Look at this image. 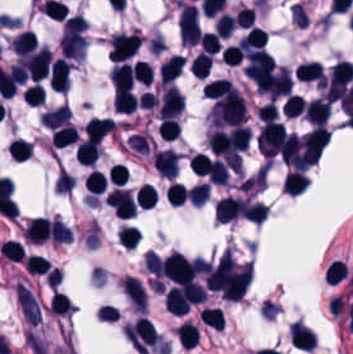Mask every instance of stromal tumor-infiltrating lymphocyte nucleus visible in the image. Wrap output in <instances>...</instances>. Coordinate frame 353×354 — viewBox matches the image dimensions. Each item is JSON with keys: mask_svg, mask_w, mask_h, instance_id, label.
Instances as JSON below:
<instances>
[{"mask_svg": "<svg viewBox=\"0 0 353 354\" xmlns=\"http://www.w3.org/2000/svg\"><path fill=\"white\" fill-rule=\"evenodd\" d=\"M177 27L180 41L184 45L192 46L200 41L202 32L195 4L180 1Z\"/></svg>", "mask_w": 353, "mask_h": 354, "instance_id": "bc302bb0", "label": "stromal tumor-infiltrating lymphocyte nucleus"}, {"mask_svg": "<svg viewBox=\"0 0 353 354\" xmlns=\"http://www.w3.org/2000/svg\"><path fill=\"white\" fill-rule=\"evenodd\" d=\"M141 40L136 32H117L111 37L109 54L113 62H122L132 57Z\"/></svg>", "mask_w": 353, "mask_h": 354, "instance_id": "52c7bb5b", "label": "stromal tumor-infiltrating lymphocyte nucleus"}, {"mask_svg": "<svg viewBox=\"0 0 353 354\" xmlns=\"http://www.w3.org/2000/svg\"><path fill=\"white\" fill-rule=\"evenodd\" d=\"M184 100L185 98L181 91L169 85L161 95L159 119H173L179 115Z\"/></svg>", "mask_w": 353, "mask_h": 354, "instance_id": "3290ff9b", "label": "stromal tumor-infiltrating lymphocyte nucleus"}, {"mask_svg": "<svg viewBox=\"0 0 353 354\" xmlns=\"http://www.w3.org/2000/svg\"><path fill=\"white\" fill-rule=\"evenodd\" d=\"M49 84L63 94L70 88V65L65 57H58L50 65Z\"/></svg>", "mask_w": 353, "mask_h": 354, "instance_id": "abfb95fc", "label": "stromal tumor-infiltrating lymphocyte nucleus"}, {"mask_svg": "<svg viewBox=\"0 0 353 354\" xmlns=\"http://www.w3.org/2000/svg\"><path fill=\"white\" fill-rule=\"evenodd\" d=\"M350 265L345 259L333 258L327 265L324 273L325 283L330 287H340L349 281Z\"/></svg>", "mask_w": 353, "mask_h": 354, "instance_id": "9ea309e8", "label": "stromal tumor-infiltrating lymphocyte nucleus"}, {"mask_svg": "<svg viewBox=\"0 0 353 354\" xmlns=\"http://www.w3.org/2000/svg\"><path fill=\"white\" fill-rule=\"evenodd\" d=\"M244 201L233 196H225L215 205V218L220 223H229L243 212Z\"/></svg>", "mask_w": 353, "mask_h": 354, "instance_id": "f3e2335f", "label": "stromal tumor-infiltrating lymphocyte nucleus"}, {"mask_svg": "<svg viewBox=\"0 0 353 354\" xmlns=\"http://www.w3.org/2000/svg\"><path fill=\"white\" fill-rule=\"evenodd\" d=\"M331 114V103L326 98H313L305 103L304 115L316 124L326 123Z\"/></svg>", "mask_w": 353, "mask_h": 354, "instance_id": "4f13568d", "label": "stromal tumor-infiltrating lymphocyte nucleus"}, {"mask_svg": "<svg viewBox=\"0 0 353 354\" xmlns=\"http://www.w3.org/2000/svg\"><path fill=\"white\" fill-rule=\"evenodd\" d=\"M26 242L41 243L50 238V222L43 218L32 219L23 229Z\"/></svg>", "mask_w": 353, "mask_h": 354, "instance_id": "2a367800", "label": "stromal tumor-infiltrating lymphocyte nucleus"}, {"mask_svg": "<svg viewBox=\"0 0 353 354\" xmlns=\"http://www.w3.org/2000/svg\"><path fill=\"white\" fill-rule=\"evenodd\" d=\"M115 122L112 118H92L87 124L85 131L87 138L97 142L104 140L113 132Z\"/></svg>", "mask_w": 353, "mask_h": 354, "instance_id": "4803ca6d", "label": "stromal tumor-infiltrating lymphocyte nucleus"}, {"mask_svg": "<svg viewBox=\"0 0 353 354\" xmlns=\"http://www.w3.org/2000/svg\"><path fill=\"white\" fill-rule=\"evenodd\" d=\"M205 98L218 99L225 96L237 94L238 90L233 86V84L223 78H215L209 80L204 88Z\"/></svg>", "mask_w": 353, "mask_h": 354, "instance_id": "4245b91a", "label": "stromal tumor-infiltrating lymphocyte nucleus"}, {"mask_svg": "<svg viewBox=\"0 0 353 354\" xmlns=\"http://www.w3.org/2000/svg\"><path fill=\"white\" fill-rule=\"evenodd\" d=\"M71 118L70 107L67 104H61L44 114H42L41 123L46 127L57 128L66 124Z\"/></svg>", "mask_w": 353, "mask_h": 354, "instance_id": "4c9ddf68", "label": "stromal tumor-infiltrating lymphocyte nucleus"}, {"mask_svg": "<svg viewBox=\"0 0 353 354\" xmlns=\"http://www.w3.org/2000/svg\"><path fill=\"white\" fill-rule=\"evenodd\" d=\"M117 91L124 92L132 84V69L129 64L118 63L109 76Z\"/></svg>", "mask_w": 353, "mask_h": 354, "instance_id": "2761f720", "label": "stromal tumor-infiltrating lymphocyte nucleus"}, {"mask_svg": "<svg viewBox=\"0 0 353 354\" xmlns=\"http://www.w3.org/2000/svg\"><path fill=\"white\" fill-rule=\"evenodd\" d=\"M36 32L32 30H25L18 34L11 41V49L16 55H24L29 51L37 48Z\"/></svg>", "mask_w": 353, "mask_h": 354, "instance_id": "3c572f05", "label": "stromal tumor-infiltrating lymphocyte nucleus"}, {"mask_svg": "<svg viewBox=\"0 0 353 354\" xmlns=\"http://www.w3.org/2000/svg\"><path fill=\"white\" fill-rule=\"evenodd\" d=\"M184 63L180 55H172L160 66L159 76L164 84H171L181 72Z\"/></svg>", "mask_w": 353, "mask_h": 354, "instance_id": "42bb06b2", "label": "stromal tumor-infiltrating lymphocyte nucleus"}, {"mask_svg": "<svg viewBox=\"0 0 353 354\" xmlns=\"http://www.w3.org/2000/svg\"><path fill=\"white\" fill-rule=\"evenodd\" d=\"M78 138L77 129L72 124H65L55 128L51 141L55 148H64L74 144Z\"/></svg>", "mask_w": 353, "mask_h": 354, "instance_id": "9e4306bb", "label": "stromal tumor-infiltrating lymphocyte nucleus"}, {"mask_svg": "<svg viewBox=\"0 0 353 354\" xmlns=\"http://www.w3.org/2000/svg\"><path fill=\"white\" fill-rule=\"evenodd\" d=\"M310 180L303 171H290L284 179L287 194L301 195L307 188Z\"/></svg>", "mask_w": 353, "mask_h": 354, "instance_id": "04cf8593", "label": "stromal tumor-infiltrating lymphocyte nucleus"}, {"mask_svg": "<svg viewBox=\"0 0 353 354\" xmlns=\"http://www.w3.org/2000/svg\"><path fill=\"white\" fill-rule=\"evenodd\" d=\"M292 90L291 75L287 68L281 66L277 72L270 92L271 98L279 99L290 94Z\"/></svg>", "mask_w": 353, "mask_h": 354, "instance_id": "e9af9c67", "label": "stromal tumor-infiltrating lymphocyte nucleus"}, {"mask_svg": "<svg viewBox=\"0 0 353 354\" xmlns=\"http://www.w3.org/2000/svg\"><path fill=\"white\" fill-rule=\"evenodd\" d=\"M176 336L181 348L191 350L199 341V329L185 321L176 328Z\"/></svg>", "mask_w": 353, "mask_h": 354, "instance_id": "782c7336", "label": "stromal tumor-infiltrating lymphocyte nucleus"}, {"mask_svg": "<svg viewBox=\"0 0 353 354\" xmlns=\"http://www.w3.org/2000/svg\"><path fill=\"white\" fill-rule=\"evenodd\" d=\"M295 77L302 82L320 81L324 79V73L318 63L308 61L298 65Z\"/></svg>", "mask_w": 353, "mask_h": 354, "instance_id": "cac63f63", "label": "stromal tumor-infiltrating lymphocyte nucleus"}, {"mask_svg": "<svg viewBox=\"0 0 353 354\" xmlns=\"http://www.w3.org/2000/svg\"><path fill=\"white\" fill-rule=\"evenodd\" d=\"M99 153L98 145L94 140L86 139L78 145L75 154L76 159L82 165H92Z\"/></svg>", "mask_w": 353, "mask_h": 354, "instance_id": "2e467ee5", "label": "stromal tumor-infiltrating lymphocyte nucleus"}, {"mask_svg": "<svg viewBox=\"0 0 353 354\" xmlns=\"http://www.w3.org/2000/svg\"><path fill=\"white\" fill-rule=\"evenodd\" d=\"M138 104L135 96L127 90L114 95L113 106L117 113L131 114Z\"/></svg>", "mask_w": 353, "mask_h": 354, "instance_id": "7eef579d", "label": "stromal tumor-infiltrating lymphocyte nucleus"}, {"mask_svg": "<svg viewBox=\"0 0 353 354\" xmlns=\"http://www.w3.org/2000/svg\"><path fill=\"white\" fill-rule=\"evenodd\" d=\"M135 200L141 208L151 209L157 200L155 186L145 182L136 190Z\"/></svg>", "mask_w": 353, "mask_h": 354, "instance_id": "c26a33f6", "label": "stromal tumor-infiltrating lymphocyte nucleus"}, {"mask_svg": "<svg viewBox=\"0 0 353 354\" xmlns=\"http://www.w3.org/2000/svg\"><path fill=\"white\" fill-rule=\"evenodd\" d=\"M166 197L171 206H182L189 199V190L180 182H172L167 186Z\"/></svg>", "mask_w": 353, "mask_h": 354, "instance_id": "3e0999b9", "label": "stromal tumor-infiltrating lymphocyte nucleus"}, {"mask_svg": "<svg viewBox=\"0 0 353 354\" xmlns=\"http://www.w3.org/2000/svg\"><path fill=\"white\" fill-rule=\"evenodd\" d=\"M213 56L199 53L195 56L194 60L190 65L191 74L198 79H205L212 63Z\"/></svg>", "mask_w": 353, "mask_h": 354, "instance_id": "a0a3295f", "label": "stromal tumor-infiltrating lymphocyte nucleus"}, {"mask_svg": "<svg viewBox=\"0 0 353 354\" xmlns=\"http://www.w3.org/2000/svg\"><path fill=\"white\" fill-rule=\"evenodd\" d=\"M87 189L95 194H102L108 186V179L105 174L99 170H92L85 180Z\"/></svg>", "mask_w": 353, "mask_h": 354, "instance_id": "b6af03f8", "label": "stromal tumor-infiltrating lymphocyte nucleus"}, {"mask_svg": "<svg viewBox=\"0 0 353 354\" xmlns=\"http://www.w3.org/2000/svg\"><path fill=\"white\" fill-rule=\"evenodd\" d=\"M200 317L207 326L224 329V317L219 307H205L201 311Z\"/></svg>", "mask_w": 353, "mask_h": 354, "instance_id": "6c763739", "label": "stromal tumor-infiltrating lymphocyte nucleus"}, {"mask_svg": "<svg viewBox=\"0 0 353 354\" xmlns=\"http://www.w3.org/2000/svg\"><path fill=\"white\" fill-rule=\"evenodd\" d=\"M133 80L138 81L142 84L149 85L153 80V72L151 64L144 60H137L132 70Z\"/></svg>", "mask_w": 353, "mask_h": 354, "instance_id": "fa64b396", "label": "stromal tumor-infiltrating lymphocyte nucleus"}, {"mask_svg": "<svg viewBox=\"0 0 353 354\" xmlns=\"http://www.w3.org/2000/svg\"><path fill=\"white\" fill-rule=\"evenodd\" d=\"M118 242L124 248H133L141 239L139 231L136 227L122 226L117 232Z\"/></svg>", "mask_w": 353, "mask_h": 354, "instance_id": "21d57d70", "label": "stromal tumor-infiltrating lymphocyte nucleus"}, {"mask_svg": "<svg viewBox=\"0 0 353 354\" xmlns=\"http://www.w3.org/2000/svg\"><path fill=\"white\" fill-rule=\"evenodd\" d=\"M45 88L41 84H34L22 92V99L27 105L40 106L45 100Z\"/></svg>", "mask_w": 353, "mask_h": 354, "instance_id": "02f42fee", "label": "stromal tumor-infiltrating lymphocyte nucleus"}, {"mask_svg": "<svg viewBox=\"0 0 353 354\" xmlns=\"http://www.w3.org/2000/svg\"><path fill=\"white\" fill-rule=\"evenodd\" d=\"M218 35L230 37L238 25L237 17L232 13H223L215 22Z\"/></svg>", "mask_w": 353, "mask_h": 354, "instance_id": "18da8d3c", "label": "stromal tumor-infiltrating lymphocyte nucleus"}, {"mask_svg": "<svg viewBox=\"0 0 353 354\" xmlns=\"http://www.w3.org/2000/svg\"><path fill=\"white\" fill-rule=\"evenodd\" d=\"M72 232L57 218L50 224V239L55 243H69Z\"/></svg>", "mask_w": 353, "mask_h": 354, "instance_id": "8379cbfb", "label": "stromal tumor-infiltrating lymphocyte nucleus"}, {"mask_svg": "<svg viewBox=\"0 0 353 354\" xmlns=\"http://www.w3.org/2000/svg\"><path fill=\"white\" fill-rule=\"evenodd\" d=\"M305 105V100L301 98L298 94H291L286 98L282 105V113L288 115L289 117H297L303 111Z\"/></svg>", "mask_w": 353, "mask_h": 354, "instance_id": "023d44f5", "label": "stromal tumor-infiltrating lymphocyte nucleus"}, {"mask_svg": "<svg viewBox=\"0 0 353 354\" xmlns=\"http://www.w3.org/2000/svg\"><path fill=\"white\" fill-rule=\"evenodd\" d=\"M8 149L12 158L26 161L31 153L32 145L23 138L17 137L10 143Z\"/></svg>", "mask_w": 353, "mask_h": 354, "instance_id": "afbf053c", "label": "stromal tumor-infiltrating lymphocyte nucleus"}, {"mask_svg": "<svg viewBox=\"0 0 353 354\" xmlns=\"http://www.w3.org/2000/svg\"><path fill=\"white\" fill-rule=\"evenodd\" d=\"M245 215L247 220L263 223L266 218V208L264 204L245 201L244 203Z\"/></svg>", "mask_w": 353, "mask_h": 354, "instance_id": "1d375fb5", "label": "stromal tumor-infiltrating lymphocyte nucleus"}, {"mask_svg": "<svg viewBox=\"0 0 353 354\" xmlns=\"http://www.w3.org/2000/svg\"><path fill=\"white\" fill-rule=\"evenodd\" d=\"M222 56L225 64L239 65L244 54L240 44H233L223 51Z\"/></svg>", "mask_w": 353, "mask_h": 354, "instance_id": "84afeb40", "label": "stromal tumor-infiltrating lymphocyte nucleus"}, {"mask_svg": "<svg viewBox=\"0 0 353 354\" xmlns=\"http://www.w3.org/2000/svg\"><path fill=\"white\" fill-rule=\"evenodd\" d=\"M277 113H278L277 107L272 100L263 103L261 105H258L257 107V116L258 119L260 120H264L267 122L273 120L277 115Z\"/></svg>", "mask_w": 353, "mask_h": 354, "instance_id": "a6e9041d", "label": "stromal tumor-infiltrating lymphocyte nucleus"}]
</instances>
